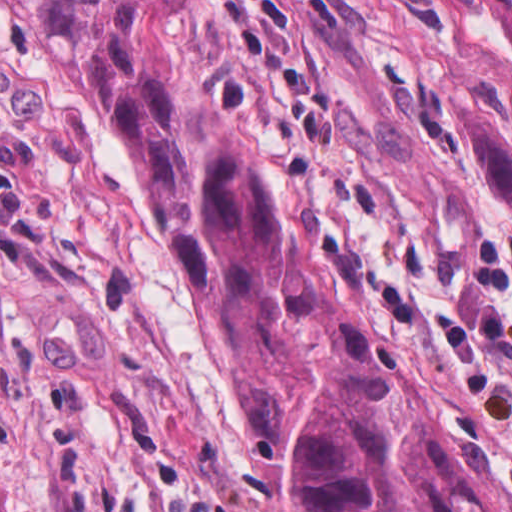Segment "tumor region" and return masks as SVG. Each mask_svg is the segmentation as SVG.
I'll return each instance as SVG.
<instances>
[{
	"label": "tumor region",
	"instance_id": "e687c5a6",
	"mask_svg": "<svg viewBox=\"0 0 512 512\" xmlns=\"http://www.w3.org/2000/svg\"><path fill=\"white\" fill-rule=\"evenodd\" d=\"M484 1L512 52V0ZM11 2L187 248L209 338L295 512H512V479L475 453L437 376L303 265L267 162L175 43L184 0ZM450 137L495 203L512 204V124L464 75Z\"/></svg>",
	"mask_w": 512,
	"mask_h": 512
}]
</instances>
